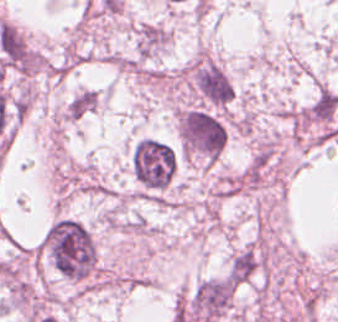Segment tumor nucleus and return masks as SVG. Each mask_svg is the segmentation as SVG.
Segmentation results:
<instances>
[{
    "instance_id": "2cbd58db",
    "label": "tumor nucleus",
    "mask_w": 338,
    "mask_h": 322,
    "mask_svg": "<svg viewBox=\"0 0 338 322\" xmlns=\"http://www.w3.org/2000/svg\"><path fill=\"white\" fill-rule=\"evenodd\" d=\"M235 292L228 274L200 278L189 293L186 310L200 322L213 320L231 310Z\"/></svg>"
},
{
    "instance_id": "2083b535",
    "label": "tumor nucleus",
    "mask_w": 338,
    "mask_h": 322,
    "mask_svg": "<svg viewBox=\"0 0 338 322\" xmlns=\"http://www.w3.org/2000/svg\"><path fill=\"white\" fill-rule=\"evenodd\" d=\"M98 104L97 93L82 89L74 95L65 105L64 119H76L89 113Z\"/></svg>"
},
{
    "instance_id": "2f306a5c",
    "label": "tumor nucleus",
    "mask_w": 338,
    "mask_h": 322,
    "mask_svg": "<svg viewBox=\"0 0 338 322\" xmlns=\"http://www.w3.org/2000/svg\"><path fill=\"white\" fill-rule=\"evenodd\" d=\"M37 249L60 273L72 279L92 276L97 245L88 226L71 216L53 220L37 242Z\"/></svg>"
},
{
    "instance_id": "8643909e",
    "label": "tumor nucleus",
    "mask_w": 338,
    "mask_h": 322,
    "mask_svg": "<svg viewBox=\"0 0 338 322\" xmlns=\"http://www.w3.org/2000/svg\"><path fill=\"white\" fill-rule=\"evenodd\" d=\"M178 137L183 155L214 160L228 138L226 120L205 105H193L179 113Z\"/></svg>"
},
{
    "instance_id": "3d1891a8",
    "label": "tumor nucleus",
    "mask_w": 338,
    "mask_h": 322,
    "mask_svg": "<svg viewBox=\"0 0 338 322\" xmlns=\"http://www.w3.org/2000/svg\"><path fill=\"white\" fill-rule=\"evenodd\" d=\"M192 93L204 103L227 106L233 102V82L228 73L210 60H196L189 71Z\"/></svg>"
},
{
    "instance_id": "5ab6c2c4",
    "label": "tumor nucleus",
    "mask_w": 338,
    "mask_h": 322,
    "mask_svg": "<svg viewBox=\"0 0 338 322\" xmlns=\"http://www.w3.org/2000/svg\"><path fill=\"white\" fill-rule=\"evenodd\" d=\"M129 163L138 196H155L170 184L175 154L161 139L143 135L132 142Z\"/></svg>"
}]
</instances>
